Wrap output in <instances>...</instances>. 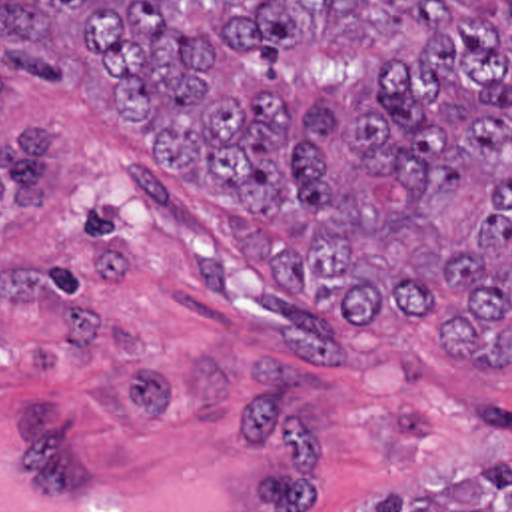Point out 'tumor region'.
Instances as JSON below:
<instances>
[{
  "mask_svg": "<svg viewBox=\"0 0 512 512\" xmlns=\"http://www.w3.org/2000/svg\"><path fill=\"white\" fill-rule=\"evenodd\" d=\"M75 55L269 275L512 370V0H0V99ZM53 159L25 117L0 205L45 207ZM370 512H512V462Z\"/></svg>",
  "mask_w": 512,
  "mask_h": 512,
  "instance_id": "1",
  "label": "tumor region"
}]
</instances>
